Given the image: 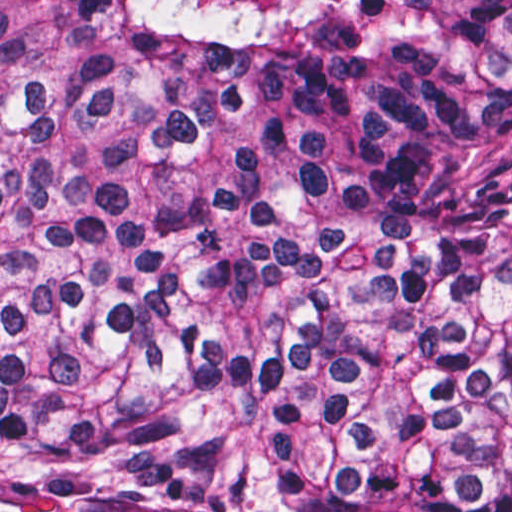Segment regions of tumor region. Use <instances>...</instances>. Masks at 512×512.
I'll list each match as a JSON object with an SVG mask.
<instances>
[{"label":"tumor region","mask_w":512,"mask_h":512,"mask_svg":"<svg viewBox=\"0 0 512 512\" xmlns=\"http://www.w3.org/2000/svg\"><path fill=\"white\" fill-rule=\"evenodd\" d=\"M0 512H512V0H0Z\"/></svg>","instance_id":"1"}]
</instances>
